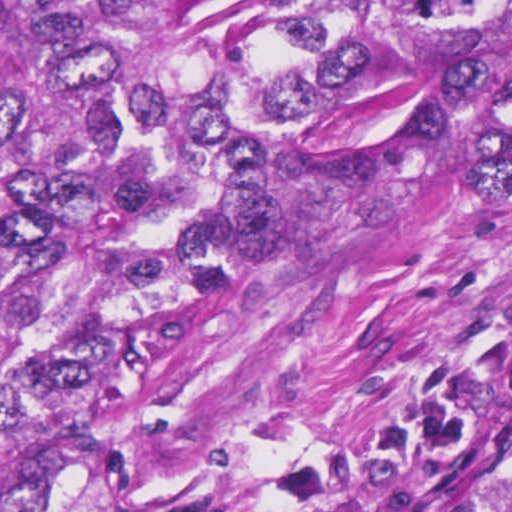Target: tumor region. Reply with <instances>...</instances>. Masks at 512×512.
Listing matches in <instances>:
<instances>
[{
	"mask_svg": "<svg viewBox=\"0 0 512 512\" xmlns=\"http://www.w3.org/2000/svg\"><path fill=\"white\" fill-rule=\"evenodd\" d=\"M508 128L512 0H0V512H127L94 458L317 204Z\"/></svg>",
	"mask_w": 512,
	"mask_h": 512,
	"instance_id": "tumor-region-1",
	"label": "tumor region"
}]
</instances>
